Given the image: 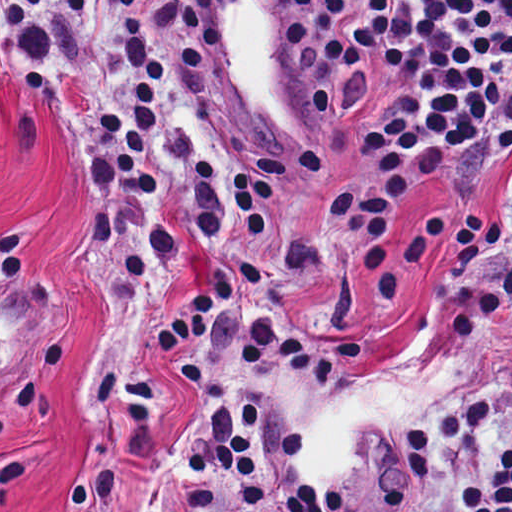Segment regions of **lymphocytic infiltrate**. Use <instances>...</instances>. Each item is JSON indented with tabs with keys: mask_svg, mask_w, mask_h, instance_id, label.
<instances>
[{
	"mask_svg": "<svg viewBox=\"0 0 512 512\" xmlns=\"http://www.w3.org/2000/svg\"><path fill=\"white\" fill-rule=\"evenodd\" d=\"M51 4L66 124L103 182L97 293L117 308L158 304L181 250L202 239L263 265L282 207L336 174L332 143L274 139L230 117L212 0H0V61ZM286 4L304 92L360 161L330 231L358 247L363 298H398L393 223L409 192L475 208L512 166V0ZM154 350L185 380L193 413L173 512H512V241L410 360L383 365L360 338L318 331L216 275ZM431 356L462 373L439 425L396 435L372 424L354 436L346 480L311 484L304 432L265 378L341 391Z\"/></svg>",
	"mask_w": 512,
	"mask_h": 512,
	"instance_id": "obj_1",
	"label": "lymphocytic infiltrate"
}]
</instances>
